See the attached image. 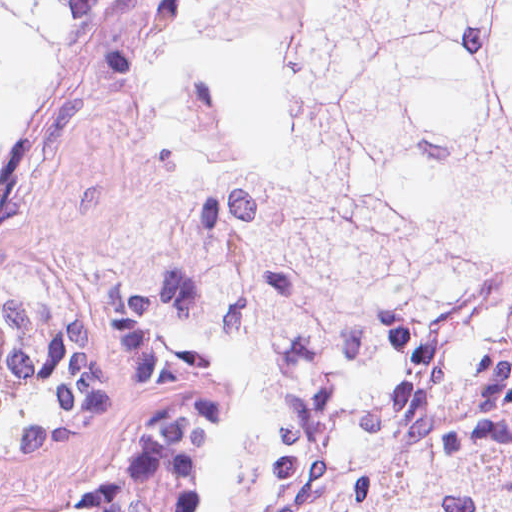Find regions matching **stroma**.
Returning <instances> with one entry per match:
<instances>
[{
	"instance_id": "obj_1",
	"label": "stroma",
	"mask_w": 512,
	"mask_h": 512,
	"mask_svg": "<svg viewBox=\"0 0 512 512\" xmlns=\"http://www.w3.org/2000/svg\"><path fill=\"white\" fill-rule=\"evenodd\" d=\"M0 1H150L85 113L16 182L0 262V499L216 512L222 382L151 347L136 264L258 135L253 1L512 0Z\"/></svg>"
}]
</instances>
